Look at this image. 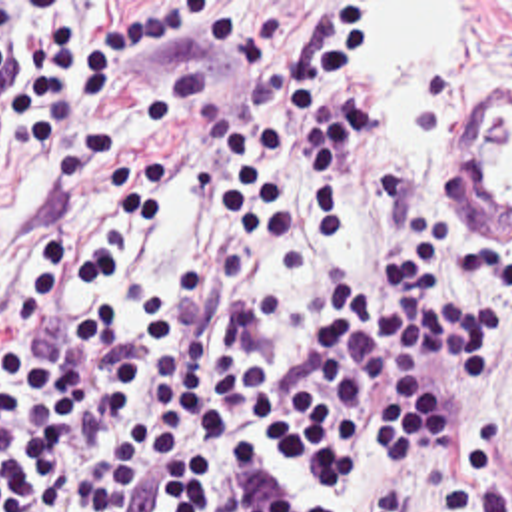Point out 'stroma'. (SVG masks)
<instances>
[{"mask_svg": "<svg viewBox=\"0 0 512 512\" xmlns=\"http://www.w3.org/2000/svg\"><path fill=\"white\" fill-rule=\"evenodd\" d=\"M0 2H9L15 10L31 16V14H39V12H65V14H319L327 6H357L361 0H0ZM349 96H351V80L331 98H349ZM458 166H460V156L448 168H444L440 174H436L432 178L431 184L425 188V192L419 198L415 214L436 192L458 190L462 194ZM407 226H405V230H407ZM405 230L401 232V236L395 240V244L389 248V252L383 256V260L379 264L359 268L375 280L377 288L391 284L395 262L401 254ZM482 238L488 240L492 236H482ZM474 254H476V250L464 252V256L456 268V286L474 290V292L486 296V292L476 282V274H474V266H472ZM355 272L357 270H353L341 278H335L323 286H295L291 296L345 294L355 280ZM427 365L431 369L434 381L446 385L458 399L462 415H464V433L468 429L472 413H476L482 407H496L512 435V385L500 377V371L482 385L454 387L452 383H448L444 379L442 351L438 347H431V345H429V353H427ZM261 447L269 455H273L283 467L289 469L285 455L281 451L279 439L275 435L265 433ZM301 485H303V481H301Z\"/></svg>", "mask_w": 512, "mask_h": 512, "instance_id": "obj_1", "label": "stroma"}]
</instances>
